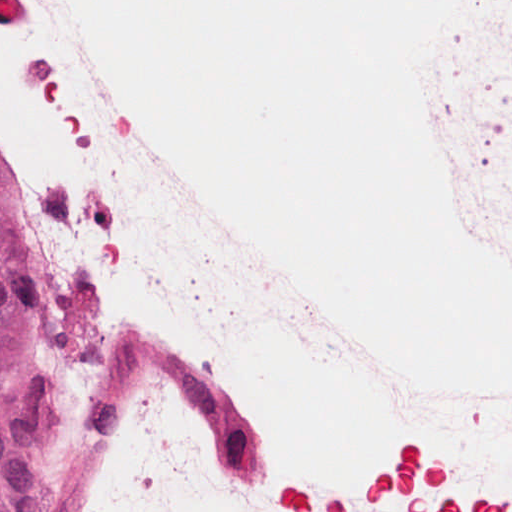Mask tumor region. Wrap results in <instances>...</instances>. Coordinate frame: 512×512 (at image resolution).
Returning <instances> with one entry per match:
<instances>
[{
	"instance_id": "tumor-region-1",
	"label": "tumor region",
	"mask_w": 512,
	"mask_h": 512,
	"mask_svg": "<svg viewBox=\"0 0 512 512\" xmlns=\"http://www.w3.org/2000/svg\"><path fill=\"white\" fill-rule=\"evenodd\" d=\"M39 360L9 194L0 182V463L37 452Z\"/></svg>"
}]
</instances>
